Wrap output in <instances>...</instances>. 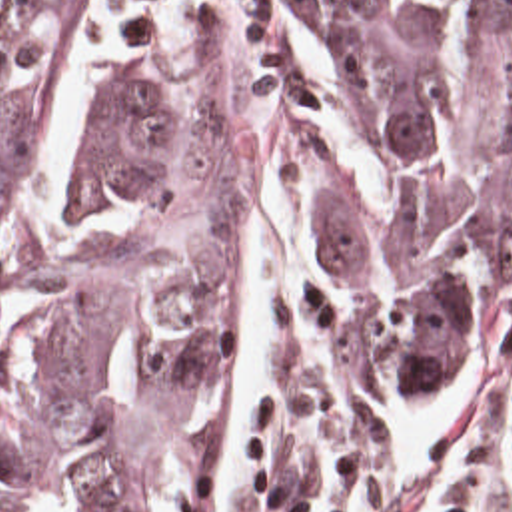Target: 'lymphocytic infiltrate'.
<instances>
[{
    "mask_svg": "<svg viewBox=\"0 0 512 512\" xmlns=\"http://www.w3.org/2000/svg\"><path fill=\"white\" fill-rule=\"evenodd\" d=\"M439 436L391 512H503V448L512 452V388L433 420ZM403 430L349 440L315 512H355L375 460Z\"/></svg>",
    "mask_w": 512,
    "mask_h": 512,
    "instance_id": "obj_1",
    "label": "lymphocytic infiltrate"
}]
</instances>
